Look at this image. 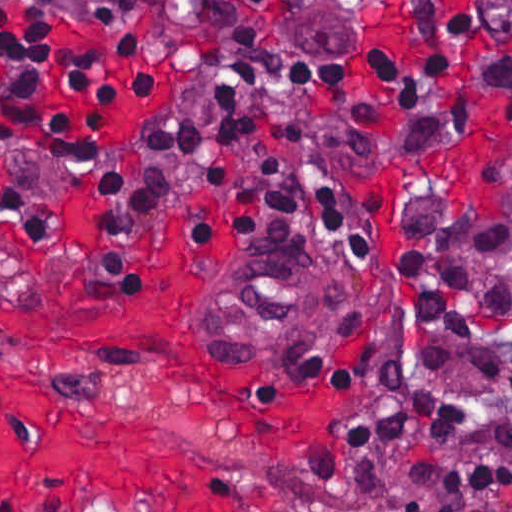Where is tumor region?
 Segmentation results:
<instances>
[{
	"instance_id": "e687c5a6",
	"label": "tumor region",
	"mask_w": 512,
	"mask_h": 512,
	"mask_svg": "<svg viewBox=\"0 0 512 512\" xmlns=\"http://www.w3.org/2000/svg\"><path fill=\"white\" fill-rule=\"evenodd\" d=\"M290 58L325 75L369 65L387 23L445 7L512 49V0H251ZM147 0H0V38L23 21L49 16L78 32L126 20ZM347 290V288H346Z\"/></svg>"
}]
</instances>
